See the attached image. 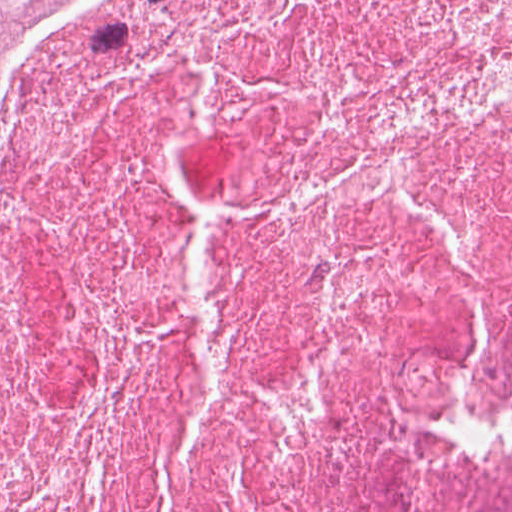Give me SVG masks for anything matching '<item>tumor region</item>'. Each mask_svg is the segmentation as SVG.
<instances>
[{"label": "tumor region", "mask_w": 512, "mask_h": 512, "mask_svg": "<svg viewBox=\"0 0 512 512\" xmlns=\"http://www.w3.org/2000/svg\"><path fill=\"white\" fill-rule=\"evenodd\" d=\"M59 0H0V168L26 70Z\"/></svg>", "instance_id": "e687c5a6"}]
</instances>
